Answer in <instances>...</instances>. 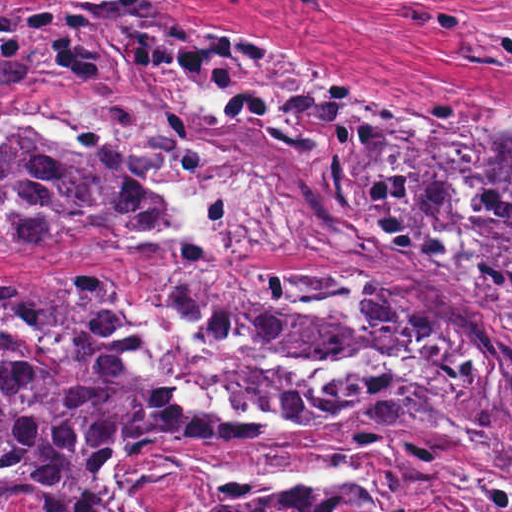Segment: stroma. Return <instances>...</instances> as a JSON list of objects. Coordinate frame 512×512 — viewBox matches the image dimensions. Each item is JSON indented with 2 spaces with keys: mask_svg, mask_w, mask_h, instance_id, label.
<instances>
[{
  "mask_svg": "<svg viewBox=\"0 0 512 512\" xmlns=\"http://www.w3.org/2000/svg\"><path fill=\"white\" fill-rule=\"evenodd\" d=\"M0 0V512L1 271H277L343 267L323 242L329 232L366 228L282 180L239 163L155 97L137 90L29 82L1 76ZM485 19L512 14L456 0ZM179 20L214 27L290 62L319 69L387 111L430 122L431 105L474 131L455 222L443 231H377L427 242L477 226L489 183L490 149L512 125V76L453 64L459 38L444 29L391 21L369 0H331L327 12L302 0H165ZM137 119L207 157L263 204L310 221L296 246L277 251L187 250L130 239L60 241L1 250V135H110ZM297 490L379 495L384 512H512V470L459 451L408 423L268 434L184 451H153L128 475L130 504L144 512H208Z\"/></svg>",
  "mask_w": 512,
  "mask_h": 512,
  "instance_id": "stroma-1",
  "label": "stroma"
}]
</instances>
